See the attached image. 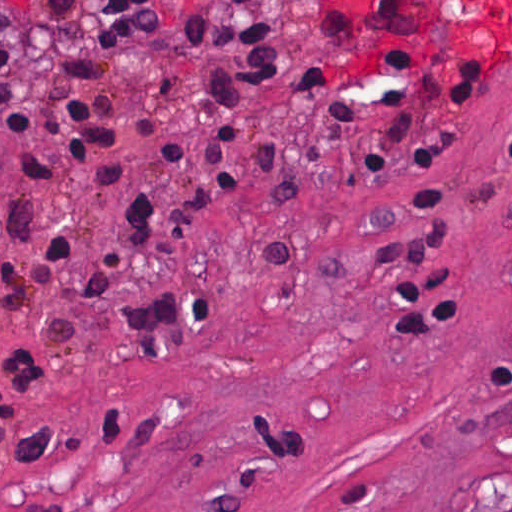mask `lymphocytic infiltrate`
Wrapping results in <instances>:
<instances>
[{
  "label": "lymphocytic infiltrate",
  "instance_id": "obj_1",
  "mask_svg": "<svg viewBox=\"0 0 512 512\" xmlns=\"http://www.w3.org/2000/svg\"><path fill=\"white\" fill-rule=\"evenodd\" d=\"M44 12L65 14L76 0H36ZM278 18H247L186 3L180 18L181 44L204 62L199 105L206 125L202 146L186 136L159 143L155 158L190 167V181L171 192L139 190L116 204L112 217L121 244L139 256H160L186 249L207 210L229 197L236 187L240 143L249 111L250 93L274 84L283 66V35ZM161 23L155 0H113L98 18V37L106 60L96 53L62 58L50 79L48 95L54 119L43 135L55 145L49 157L35 150L23 155L38 177L56 185L59 168L76 170L101 188H111L124 175L116 152L121 140L152 131L158 115L139 118L132 131H120L122 98L108 87L120 72L125 46ZM381 64L397 72L425 103L412 107L397 87H378L377 108L389 117L379 120L356 99L348 84L328 66L316 62L300 74L291 93L323 110L330 130H347L368 121L375 127L365 144L311 164H294L272 141L256 145L264 186L280 201L307 200L329 171L356 166L368 171L374 184L385 176L433 169L441 165L440 147L429 142L425 124L433 115H459L474 110L484 92L492 59L474 62H403L374 37ZM14 47L0 46V133L35 136L26 104L13 92ZM505 149L512 159V133ZM49 193L14 203L6 227L19 242H33L40 211ZM446 208L444 186L414 184L408 190L406 224L429 220ZM335 241H269L259 249V264L267 271H289L320 258H347ZM69 288L76 299L103 315L101 329L122 339L142 357L166 352L208 326L219 312V299L207 292L166 289L129 292L95 254L54 232L37 262L26 264L0 244V325L27 320L48 339L67 338L74 323L42 308L40 298L51 288ZM398 335H451L461 331L470 310L462 307L452 275L428 269L405 278L398 294ZM51 381L50 370L26 346L0 347V418L21 404L41 398L46 390L11 408ZM11 408V409H9Z\"/></svg>",
  "mask_w": 512,
  "mask_h": 512
}]
</instances>
